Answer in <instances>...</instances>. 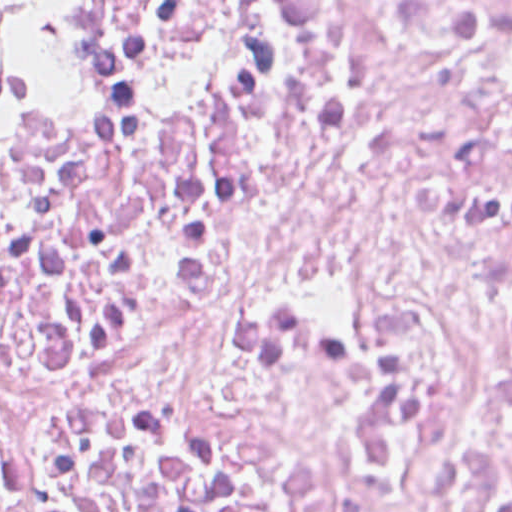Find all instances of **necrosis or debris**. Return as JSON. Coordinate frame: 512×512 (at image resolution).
<instances>
[{
  "mask_svg": "<svg viewBox=\"0 0 512 512\" xmlns=\"http://www.w3.org/2000/svg\"><path fill=\"white\" fill-rule=\"evenodd\" d=\"M0 512H512V0H14Z\"/></svg>",
  "mask_w": 512,
  "mask_h": 512,
  "instance_id": "obj_1",
  "label": "necrosis or debris"
}]
</instances>
